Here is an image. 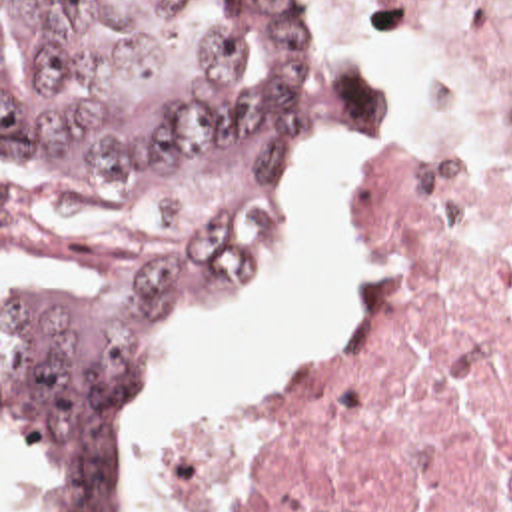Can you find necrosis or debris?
Listing matches in <instances>:
<instances>
[{
    "label": "necrosis or debris",
    "instance_id": "1",
    "mask_svg": "<svg viewBox=\"0 0 512 512\" xmlns=\"http://www.w3.org/2000/svg\"><path fill=\"white\" fill-rule=\"evenodd\" d=\"M363 1L425 20L512 112V0ZM363 234L351 340L278 400L172 432L182 512H512V164L399 144Z\"/></svg>",
    "mask_w": 512,
    "mask_h": 512
}]
</instances>
